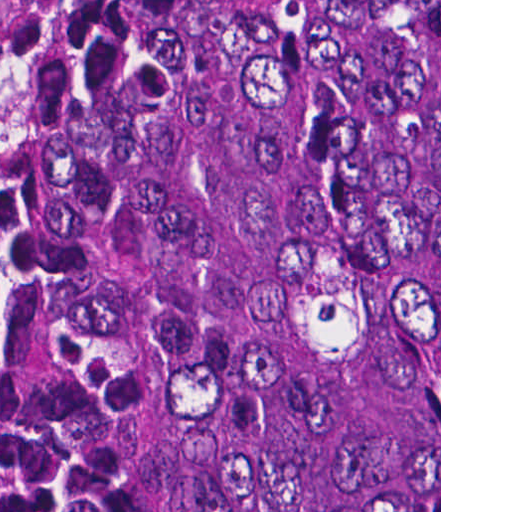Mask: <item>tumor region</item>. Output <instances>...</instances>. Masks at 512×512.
I'll list each match as a JSON object with an SVG mask.
<instances>
[{"mask_svg":"<svg viewBox=\"0 0 512 512\" xmlns=\"http://www.w3.org/2000/svg\"><path fill=\"white\" fill-rule=\"evenodd\" d=\"M0 512H439V0H0Z\"/></svg>","mask_w":512,"mask_h":512,"instance_id":"e687c5a6","label":"tumor region"}]
</instances>
